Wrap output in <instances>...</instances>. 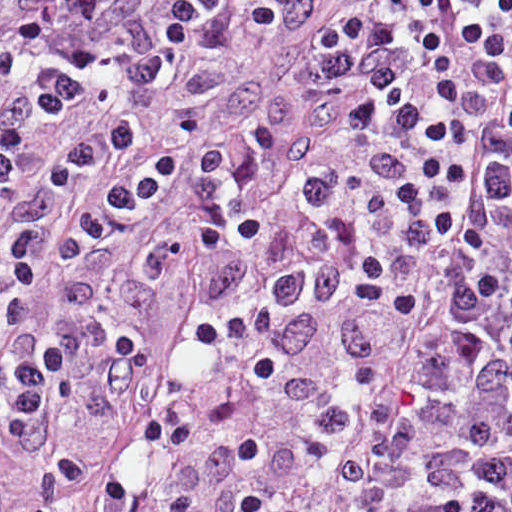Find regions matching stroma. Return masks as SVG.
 Listing matches in <instances>:
<instances>
[{
    "label": "stroma",
    "mask_w": 512,
    "mask_h": 512,
    "mask_svg": "<svg viewBox=\"0 0 512 512\" xmlns=\"http://www.w3.org/2000/svg\"><path fill=\"white\" fill-rule=\"evenodd\" d=\"M376 0H316L295 34L220 47L198 95L219 145L268 125L271 194L334 137L328 28ZM356 242L349 204L298 210L177 262L60 400L35 457L0 440V512H344L314 462V356Z\"/></svg>",
    "instance_id": "stroma-1"
}]
</instances>
